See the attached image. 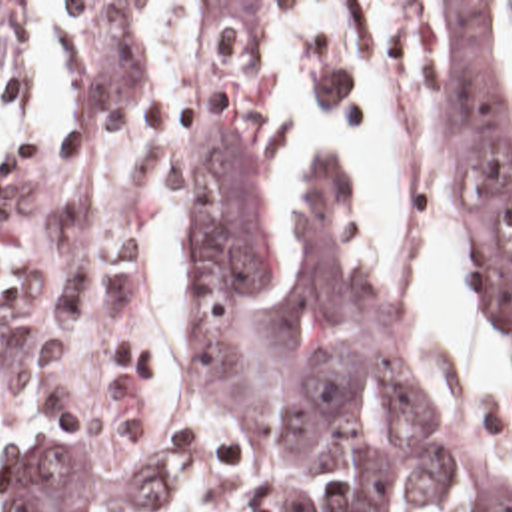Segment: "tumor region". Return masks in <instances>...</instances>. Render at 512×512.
I'll list each match as a JSON object with an SVG mask.
<instances>
[{"instance_id":"e687c5a6","label":"tumor region","mask_w":512,"mask_h":512,"mask_svg":"<svg viewBox=\"0 0 512 512\" xmlns=\"http://www.w3.org/2000/svg\"><path fill=\"white\" fill-rule=\"evenodd\" d=\"M37 0H0V48ZM453 150L467 262L512 341V2L453 10ZM191 361L267 512H512L425 409L317 176L293 285L279 268L265 150L229 104L205 106L187 158ZM0 453L1 512L161 511L155 459L101 467L91 445L17 435Z\"/></svg>"}]
</instances>
